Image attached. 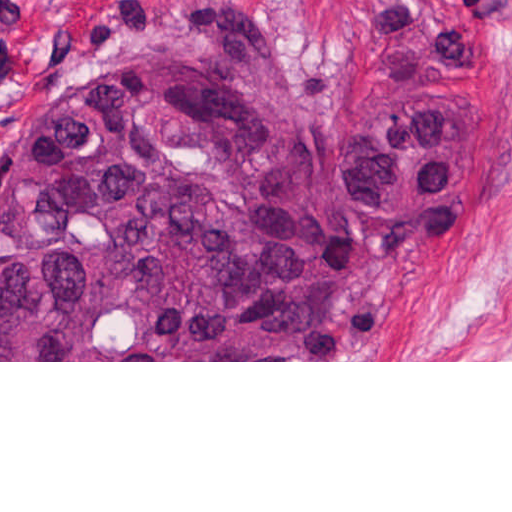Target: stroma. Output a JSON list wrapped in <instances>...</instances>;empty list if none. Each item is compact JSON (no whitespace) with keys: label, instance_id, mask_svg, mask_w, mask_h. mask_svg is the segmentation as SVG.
Returning a JSON list of instances; mask_svg holds the SVG:
<instances>
[{"label":"stroma","instance_id":"35a3bbf8","mask_svg":"<svg viewBox=\"0 0 512 512\" xmlns=\"http://www.w3.org/2000/svg\"><path fill=\"white\" fill-rule=\"evenodd\" d=\"M197 0H0V159L40 140L96 87L155 69ZM270 43L316 123L353 110L382 0H222ZM498 29L483 83L509 147L414 227L384 200L343 185L372 243L336 279L314 331L270 358L0 362H512V0H481Z\"/></svg>","mask_w":512,"mask_h":512}]
</instances>
